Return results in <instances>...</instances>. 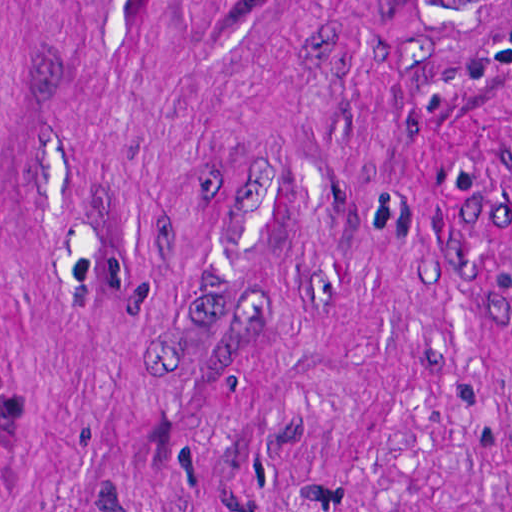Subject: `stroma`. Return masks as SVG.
<instances>
[{"label":"stroma","mask_w":512,"mask_h":512,"mask_svg":"<svg viewBox=\"0 0 512 512\" xmlns=\"http://www.w3.org/2000/svg\"><path fill=\"white\" fill-rule=\"evenodd\" d=\"M0 512H512V0H0Z\"/></svg>","instance_id":"35a3bbf8"}]
</instances>
